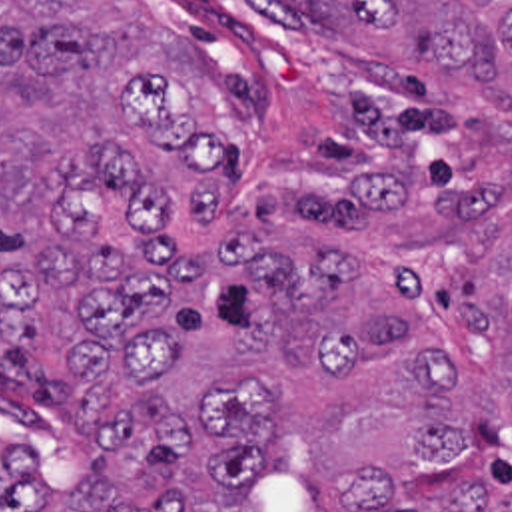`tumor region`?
<instances>
[{
    "instance_id": "tumor-region-1",
    "label": "tumor region",
    "mask_w": 512,
    "mask_h": 512,
    "mask_svg": "<svg viewBox=\"0 0 512 512\" xmlns=\"http://www.w3.org/2000/svg\"><path fill=\"white\" fill-rule=\"evenodd\" d=\"M378 58L334 172L226 186L206 80L131 0H0V512H512V0H286Z\"/></svg>"
}]
</instances>
